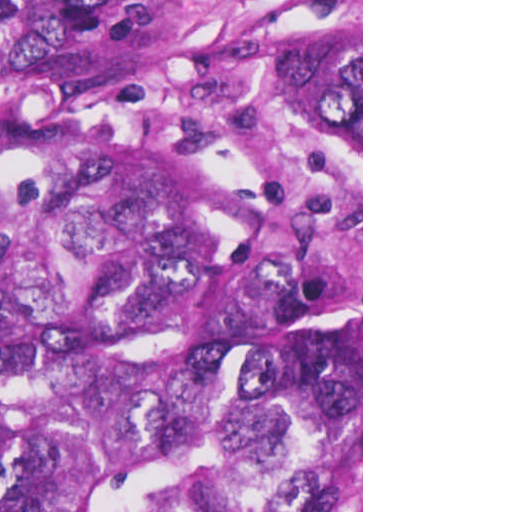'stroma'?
<instances>
[{"instance_id": "35a3bbf8", "label": "stroma", "mask_w": 512, "mask_h": 512, "mask_svg": "<svg viewBox=\"0 0 512 512\" xmlns=\"http://www.w3.org/2000/svg\"><path fill=\"white\" fill-rule=\"evenodd\" d=\"M0 1H361V425L355 455L327 512H363V0H0Z\"/></svg>"}]
</instances>
